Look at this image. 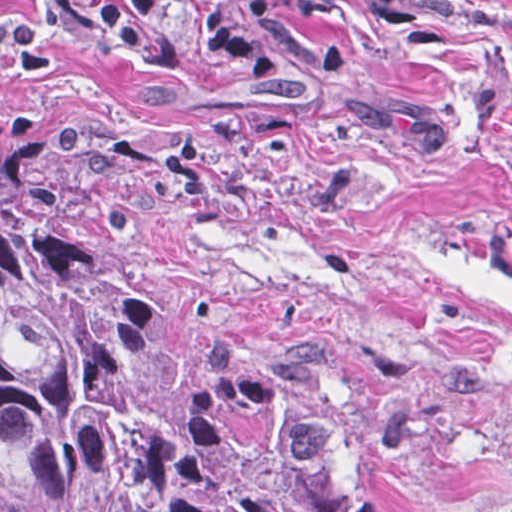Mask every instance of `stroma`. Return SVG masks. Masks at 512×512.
<instances>
[{"instance_id": "1", "label": "stroma", "mask_w": 512, "mask_h": 512, "mask_svg": "<svg viewBox=\"0 0 512 512\" xmlns=\"http://www.w3.org/2000/svg\"><path fill=\"white\" fill-rule=\"evenodd\" d=\"M230 2L269 83L180 4L112 60L0 0V145L75 174L196 369L351 346L299 427L306 505L512 512V0Z\"/></svg>"}]
</instances>
